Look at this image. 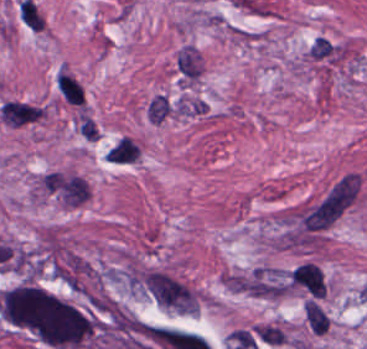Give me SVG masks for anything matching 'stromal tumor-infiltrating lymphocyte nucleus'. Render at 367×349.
<instances>
[{"label": "stromal tumor-infiltrating lymphocyte nucleus", "instance_id": "obj_1", "mask_svg": "<svg viewBox=\"0 0 367 349\" xmlns=\"http://www.w3.org/2000/svg\"><path fill=\"white\" fill-rule=\"evenodd\" d=\"M56 84L68 103L83 105V94L77 83L64 72H60Z\"/></svg>", "mask_w": 367, "mask_h": 349}]
</instances>
